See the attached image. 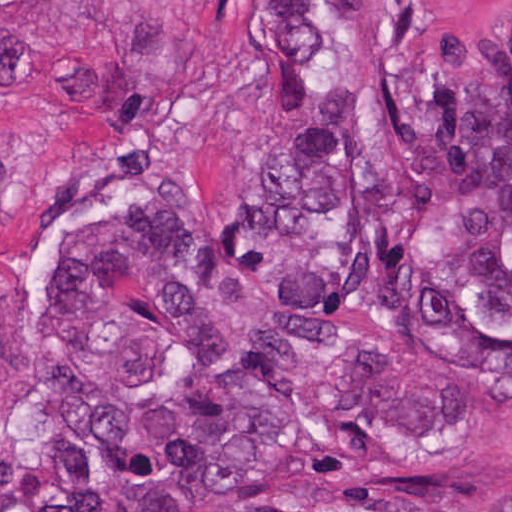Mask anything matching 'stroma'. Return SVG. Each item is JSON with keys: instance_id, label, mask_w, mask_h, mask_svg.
I'll return each instance as SVG.
<instances>
[{"instance_id": "1", "label": "stroma", "mask_w": 512, "mask_h": 512, "mask_svg": "<svg viewBox=\"0 0 512 512\" xmlns=\"http://www.w3.org/2000/svg\"><path fill=\"white\" fill-rule=\"evenodd\" d=\"M329 0H0V512H38L58 268L161 209L220 214L279 175L311 106L299 52ZM455 52L512 58V0H431ZM512 403L406 437L343 428L304 512H503Z\"/></svg>"}]
</instances>
